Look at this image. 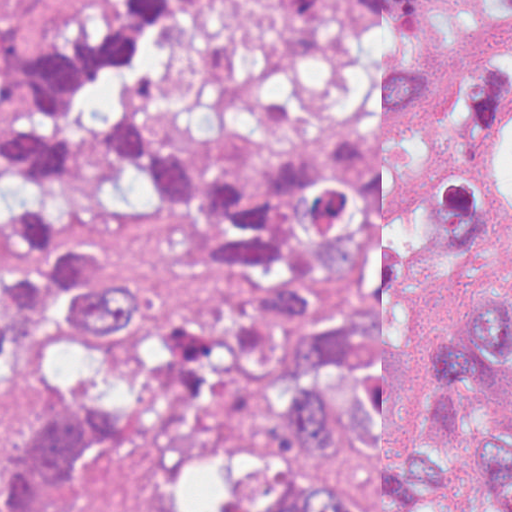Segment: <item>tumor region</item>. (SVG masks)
<instances>
[{
    "label": "tumor region",
    "mask_w": 512,
    "mask_h": 512,
    "mask_svg": "<svg viewBox=\"0 0 512 512\" xmlns=\"http://www.w3.org/2000/svg\"><path fill=\"white\" fill-rule=\"evenodd\" d=\"M0 512L136 436L383 455L271 512H450L405 441L512 425V0H122L78 34L0 1ZM512 512V437L476 450ZM124 512H172L141 502Z\"/></svg>",
    "instance_id": "1"
}]
</instances>
